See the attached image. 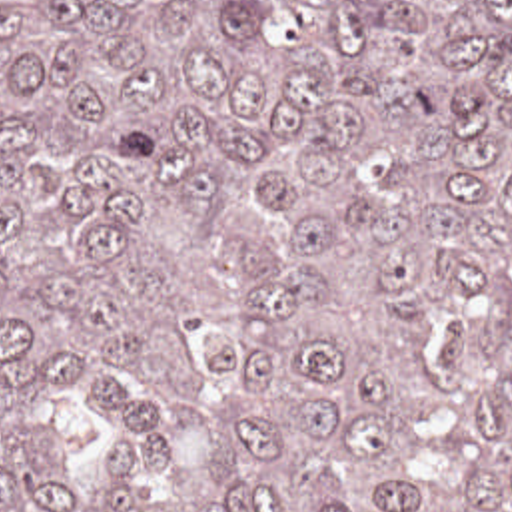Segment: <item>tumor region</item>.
<instances>
[{
  "label": "tumor region",
  "instance_id": "obj_1",
  "mask_svg": "<svg viewBox=\"0 0 512 512\" xmlns=\"http://www.w3.org/2000/svg\"><path fill=\"white\" fill-rule=\"evenodd\" d=\"M0 512H512V0H0Z\"/></svg>",
  "mask_w": 512,
  "mask_h": 512
}]
</instances>
